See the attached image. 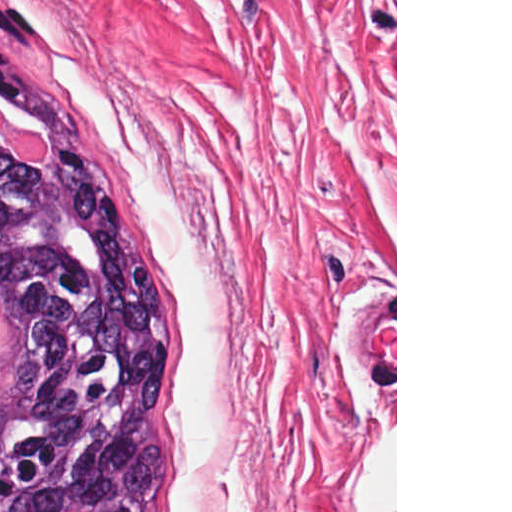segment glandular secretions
I'll return each instance as SVG.
<instances>
[{"label": "glandular secretions", "instance_id": "b5bd25d6", "mask_svg": "<svg viewBox=\"0 0 512 512\" xmlns=\"http://www.w3.org/2000/svg\"><path fill=\"white\" fill-rule=\"evenodd\" d=\"M2 106V105H0ZM4 107V106H3ZM10 116H12L13 118H15L16 120L20 121L24 126L32 129L33 131L39 133L44 141V143L46 144L47 146V134L43 131V129L38 125L36 124L34 121L22 116V115H19L9 109H7ZM0 144L2 145L1 141H0Z\"/></svg>", "mask_w": 512, "mask_h": 512}]
</instances>
